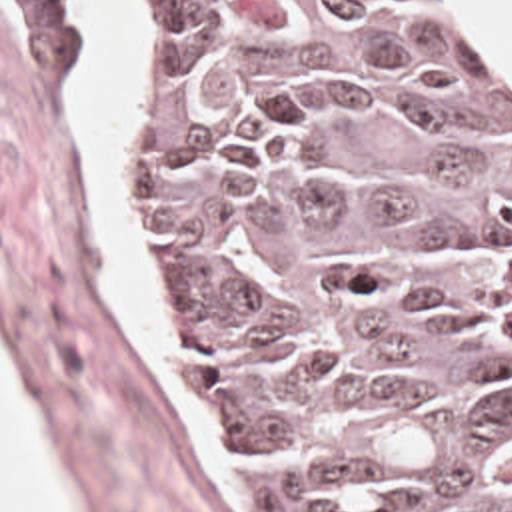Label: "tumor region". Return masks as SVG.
<instances>
[{
  "label": "tumor region",
  "instance_id": "1",
  "mask_svg": "<svg viewBox=\"0 0 512 512\" xmlns=\"http://www.w3.org/2000/svg\"><path fill=\"white\" fill-rule=\"evenodd\" d=\"M126 4L164 328L244 512H512V62L472 0Z\"/></svg>",
  "mask_w": 512,
  "mask_h": 512
}]
</instances>
